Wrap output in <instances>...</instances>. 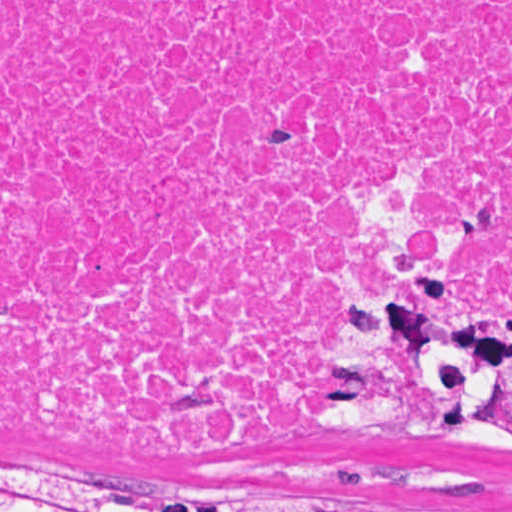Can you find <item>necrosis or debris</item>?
Wrapping results in <instances>:
<instances>
[{"label":"necrosis or debris","mask_w":512,"mask_h":512,"mask_svg":"<svg viewBox=\"0 0 512 512\" xmlns=\"http://www.w3.org/2000/svg\"><path fill=\"white\" fill-rule=\"evenodd\" d=\"M369 232L512 304V0H0V426L290 454Z\"/></svg>","instance_id":"necrosis-or-debris-1"}]
</instances>
